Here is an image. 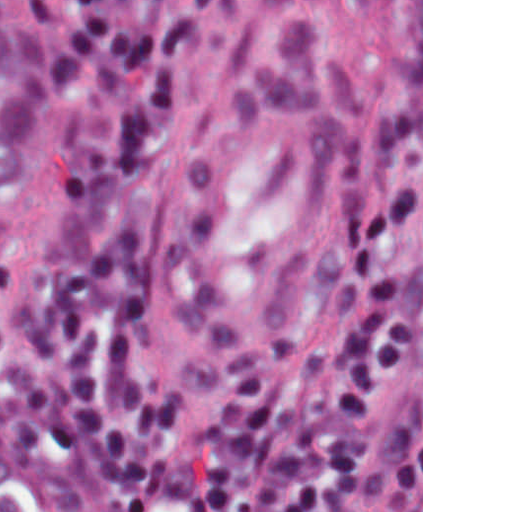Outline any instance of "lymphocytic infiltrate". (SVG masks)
<instances>
[{
  "mask_svg": "<svg viewBox=\"0 0 512 512\" xmlns=\"http://www.w3.org/2000/svg\"><path fill=\"white\" fill-rule=\"evenodd\" d=\"M230 2L55 12L41 216L0 273V418L94 470L93 512H327L294 509V403L243 380L192 422L153 345L141 194L168 104ZM0 512H14L2 489Z\"/></svg>",
  "mask_w": 512,
  "mask_h": 512,
  "instance_id": "f902f5d3",
  "label": "lymphocytic infiltrate"
}]
</instances>
